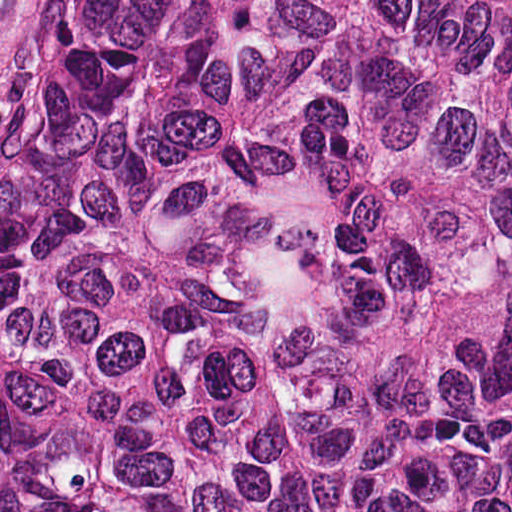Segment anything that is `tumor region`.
Returning a JSON list of instances; mask_svg holds the SVG:
<instances>
[{
  "label": "tumor region",
  "instance_id": "obj_1",
  "mask_svg": "<svg viewBox=\"0 0 512 512\" xmlns=\"http://www.w3.org/2000/svg\"><path fill=\"white\" fill-rule=\"evenodd\" d=\"M0 512H512V0H88L0 184Z\"/></svg>",
  "mask_w": 512,
  "mask_h": 512
}]
</instances>
